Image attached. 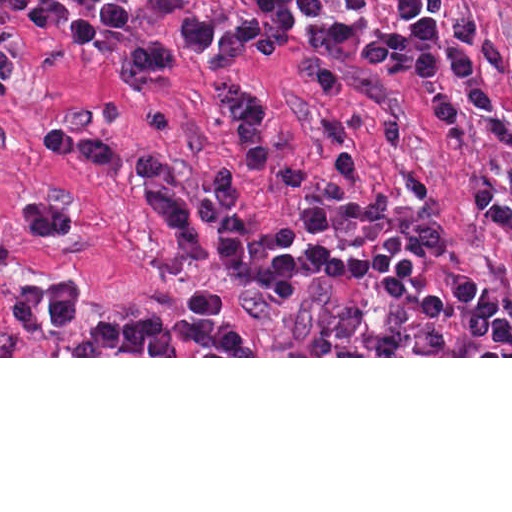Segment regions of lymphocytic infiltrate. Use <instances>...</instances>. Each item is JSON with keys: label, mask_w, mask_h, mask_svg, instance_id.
Wrapping results in <instances>:
<instances>
[{"label": "lymphocytic infiltrate", "mask_w": 512, "mask_h": 512, "mask_svg": "<svg viewBox=\"0 0 512 512\" xmlns=\"http://www.w3.org/2000/svg\"><path fill=\"white\" fill-rule=\"evenodd\" d=\"M175 2L178 0H154ZM208 18L190 15L185 39L178 45L139 44L120 65V88L131 97L188 60H200L216 85L226 116L229 142L239 161L211 170L175 161L152 151H136L116 141L80 130L60 129L47 137L50 157L92 167L117 181H151L176 186L215 201H238L259 180H270L312 237H333L347 228H368L392 211V196L373 190L358 148L345 136L330 141V166L310 165L300 155L280 150L272 127V96L267 89L234 74L248 57H260L292 80L338 104L358 96V78L340 66L292 53L231 0H204ZM431 19H441L428 39L389 36L367 51L368 70L382 78L414 85L438 131L477 138L497 149L512 167V123L500 112V100L486 76L498 73L512 85V57L503 51L489 27L461 0H412ZM0 81L26 84V69L0 35ZM474 212L501 229L512 244V169L487 182L476 194ZM10 223L31 239H63L74 229V214L53 190H27L9 207ZM305 261L321 277L349 279L373 274L375 296L409 306L415 324L441 316L438 295L409 293L423 264V247L394 232L368 256L351 259L319 242L306 248ZM451 302L461 320L483 328L493 343L512 351V311L506 298L480 276L454 270L447 279ZM4 325L21 334H49L69 329L81 317V290L69 276H48L8 295L0 306Z\"/></svg>", "instance_id": "obj_1"}]
</instances>
